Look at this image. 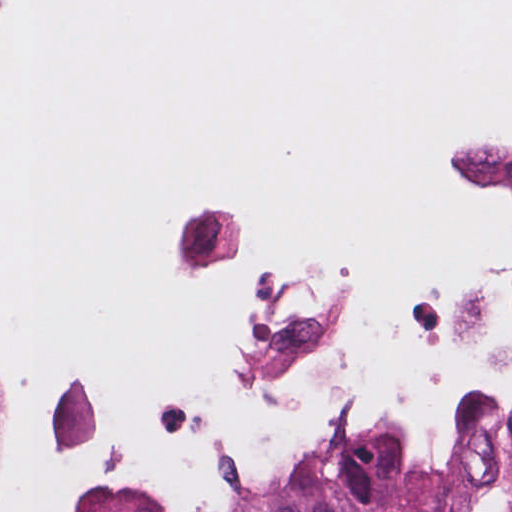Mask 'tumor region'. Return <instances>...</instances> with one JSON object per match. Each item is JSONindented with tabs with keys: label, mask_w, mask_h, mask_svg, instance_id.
<instances>
[{
	"label": "tumor region",
	"mask_w": 512,
	"mask_h": 512,
	"mask_svg": "<svg viewBox=\"0 0 512 512\" xmlns=\"http://www.w3.org/2000/svg\"><path fill=\"white\" fill-rule=\"evenodd\" d=\"M237 512H512V393H489L463 408L440 474L415 482L384 464L332 457L304 482Z\"/></svg>",
	"instance_id": "1"
}]
</instances>
